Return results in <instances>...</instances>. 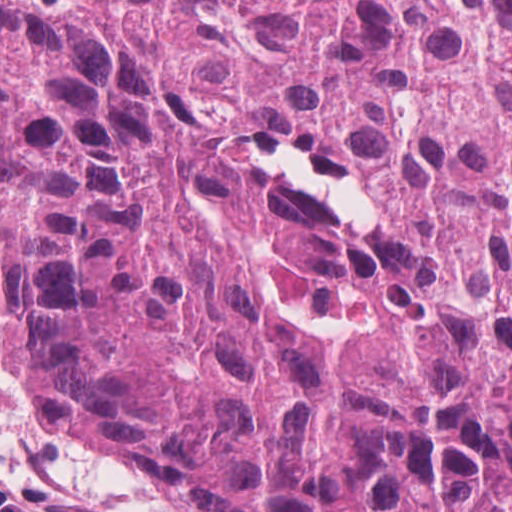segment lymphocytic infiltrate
<instances>
[{
    "label": "lymphocytic infiltrate",
    "instance_id": "f902f5d3",
    "mask_svg": "<svg viewBox=\"0 0 512 512\" xmlns=\"http://www.w3.org/2000/svg\"><path fill=\"white\" fill-rule=\"evenodd\" d=\"M0 512H31L22 499L0 484Z\"/></svg>",
    "mask_w": 512,
    "mask_h": 512
}]
</instances>
